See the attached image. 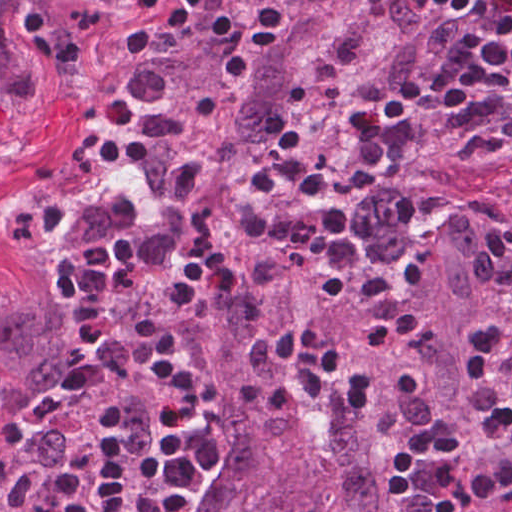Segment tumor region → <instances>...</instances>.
<instances>
[{
    "instance_id": "obj_1",
    "label": "tumor region",
    "mask_w": 512,
    "mask_h": 512,
    "mask_svg": "<svg viewBox=\"0 0 512 512\" xmlns=\"http://www.w3.org/2000/svg\"><path fill=\"white\" fill-rule=\"evenodd\" d=\"M426 0H175L145 86L131 180L84 204L39 263L0 288V368L10 391L0 437V512H27L66 448L57 430L37 441L19 417L62 396L70 314L56 279L63 255L121 241L138 250L143 289L105 301L112 326L99 367L112 385L59 408L68 432L83 408L117 403L128 444L146 448V405L124 364L149 354L158 294L201 224L220 216L235 250L231 281L176 319L175 348L202 361L208 415L203 498L193 512H425L433 473L412 499L390 498L389 463L432 414L451 427L466 373L486 335L501 251L500 213L477 199L448 204L402 228L388 214L378 158L397 127ZM287 127L296 157L328 170L307 200L272 183L264 209L299 216L341 206L365 266L394 282L375 296L319 291L323 265L245 231L244 187ZM298 323L345 361L334 387L366 375L363 413L311 405L241 404V383H291L293 363L254 367L260 337ZM52 512H78L63 505Z\"/></svg>"
}]
</instances>
